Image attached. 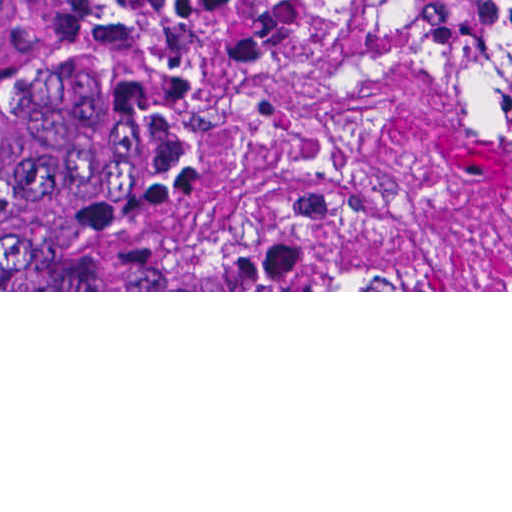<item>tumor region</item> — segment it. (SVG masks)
<instances>
[{"label":"tumor region","instance_id":"1","mask_svg":"<svg viewBox=\"0 0 512 512\" xmlns=\"http://www.w3.org/2000/svg\"><path fill=\"white\" fill-rule=\"evenodd\" d=\"M512 75V0H370ZM240 139L185 0H0V290H142V212Z\"/></svg>","mask_w":512,"mask_h":512}]
</instances>
